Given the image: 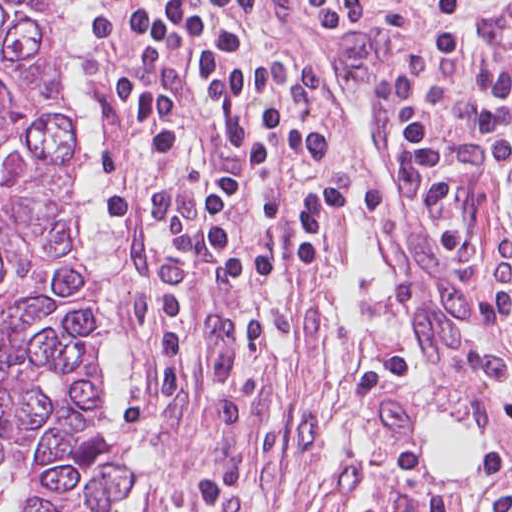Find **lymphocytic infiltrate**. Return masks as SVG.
I'll use <instances>...</instances> for the list:
<instances>
[{
	"mask_svg": "<svg viewBox=\"0 0 512 512\" xmlns=\"http://www.w3.org/2000/svg\"><path fill=\"white\" fill-rule=\"evenodd\" d=\"M95 121L96 229L194 264L149 323L145 398L186 329L251 282L303 281L350 215V133L302 54L256 57L263 15L359 18L393 149L412 153L468 281L512 328V1L76 0Z\"/></svg>",
	"mask_w": 512,
	"mask_h": 512,
	"instance_id": "f902f5d3",
	"label": "lymphocytic infiltrate"
}]
</instances>
